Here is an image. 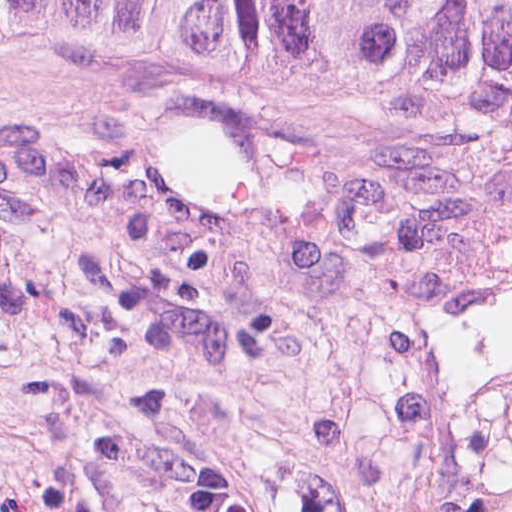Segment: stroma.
<instances>
[{
	"label": "stroma",
	"instance_id": "1",
	"mask_svg": "<svg viewBox=\"0 0 512 512\" xmlns=\"http://www.w3.org/2000/svg\"><path fill=\"white\" fill-rule=\"evenodd\" d=\"M0 512H512V85L0 34Z\"/></svg>",
	"mask_w": 512,
	"mask_h": 512
}]
</instances>
